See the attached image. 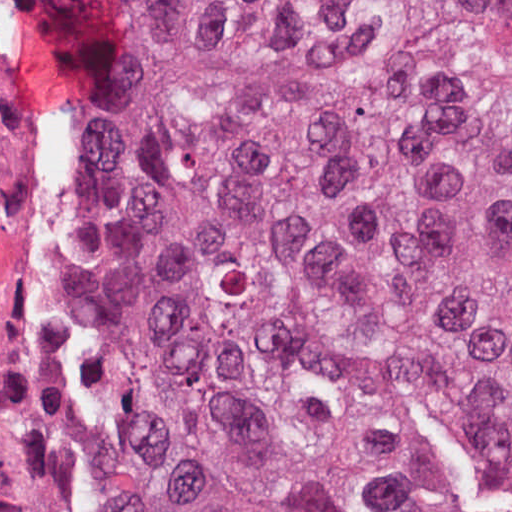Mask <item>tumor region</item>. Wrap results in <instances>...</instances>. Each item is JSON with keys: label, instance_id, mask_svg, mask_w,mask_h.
Masks as SVG:
<instances>
[{"label": "tumor region", "instance_id": "e687c5a6", "mask_svg": "<svg viewBox=\"0 0 512 512\" xmlns=\"http://www.w3.org/2000/svg\"><path fill=\"white\" fill-rule=\"evenodd\" d=\"M169 271V512H512V0H31Z\"/></svg>", "mask_w": 512, "mask_h": 512}]
</instances>
